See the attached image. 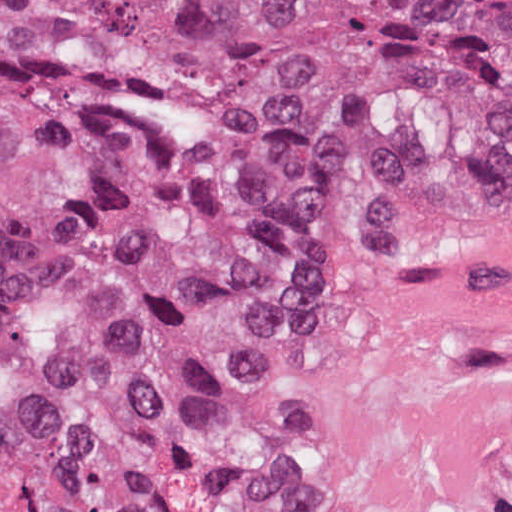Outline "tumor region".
<instances>
[{"instance_id": "e687c5a6", "label": "tumor region", "mask_w": 512, "mask_h": 512, "mask_svg": "<svg viewBox=\"0 0 512 512\" xmlns=\"http://www.w3.org/2000/svg\"><path fill=\"white\" fill-rule=\"evenodd\" d=\"M512 196V0H0V512H255L238 309Z\"/></svg>"}]
</instances>
